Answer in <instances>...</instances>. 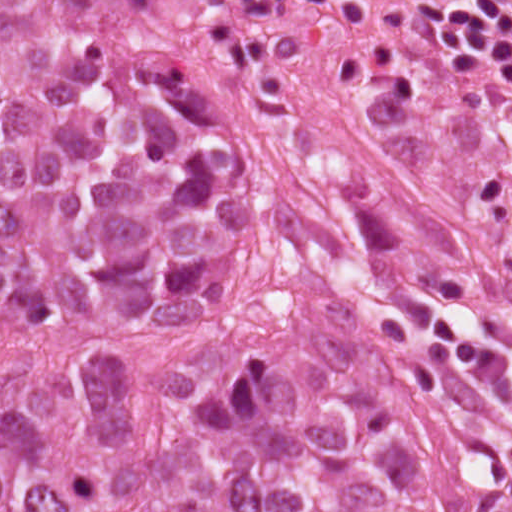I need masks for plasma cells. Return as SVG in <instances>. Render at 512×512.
Returning a JSON list of instances; mask_svg holds the SVG:
<instances>
[{
  "instance_id": "9512152a",
  "label": "plasma cells",
  "mask_w": 512,
  "mask_h": 512,
  "mask_svg": "<svg viewBox=\"0 0 512 512\" xmlns=\"http://www.w3.org/2000/svg\"><path fill=\"white\" fill-rule=\"evenodd\" d=\"M358 0H222L232 22L326 23ZM419 27L432 36L471 45L512 72V0H414Z\"/></svg>"
}]
</instances>
